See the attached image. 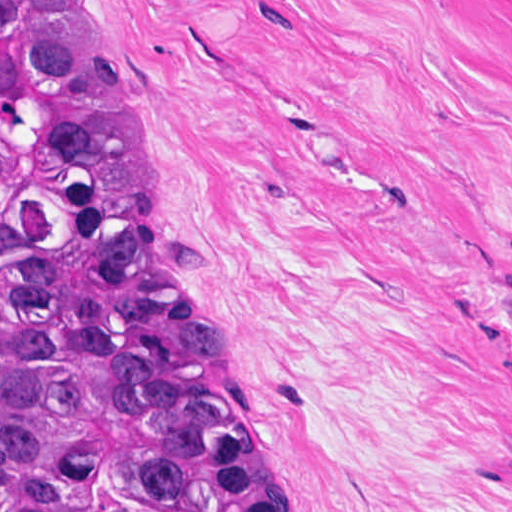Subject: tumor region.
<instances>
[{
    "label": "tumor region",
    "instance_id": "obj_1",
    "mask_svg": "<svg viewBox=\"0 0 512 512\" xmlns=\"http://www.w3.org/2000/svg\"><path fill=\"white\" fill-rule=\"evenodd\" d=\"M162 248L104 1L0 0V512H280Z\"/></svg>",
    "mask_w": 512,
    "mask_h": 512
}]
</instances>
